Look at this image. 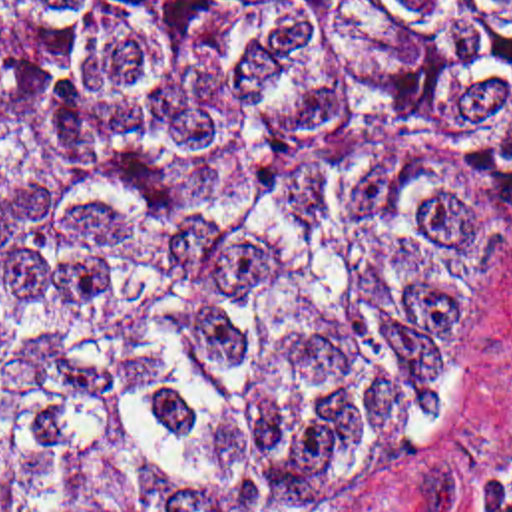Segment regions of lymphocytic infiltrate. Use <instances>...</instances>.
<instances>
[{
	"instance_id": "f902f5d3",
	"label": "lymphocytic infiltrate",
	"mask_w": 512,
	"mask_h": 512,
	"mask_svg": "<svg viewBox=\"0 0 512 512\" xmlns=\"http://www.w3.org/2000/svg\"><path fill=\"white\" fill-rule=\"evenodd\" d=\"M475 512H512V460L497 470Z\"/></svg>"
}]
</instances>
